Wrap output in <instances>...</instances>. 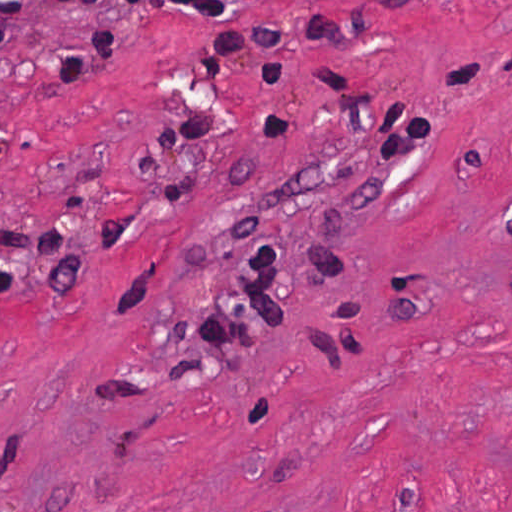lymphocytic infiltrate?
<instances>
[{"label": "lymphocytic infiltrate", "mask_w": 512, "mask_h": 512, "mask_svg": "<svg viewBox=\"0 0 512 512\" xmlns=\"http://www.w3.org/2000/svg\"><path fill=\"white\" fill-rule=\"evenodd\" d=\"M67 4L133 0H60ZM169 6L186 15L216 16L232 23L249 11L238 8L231 0H167ZM22 0H0V83L9 71V44L19 16ZM135 46L111 30L93 33L74 57L60 69V76L71 88H78L107 62ZM286 268L275 250L263 245L250 247V276L247 294L256 310V318L241 316L234 326L222 319H200L198 331L214 343H228L235 328L253 333L262 322L269 330L282 334L288 329V311L283 301ZM283 322H274L282 321Z\"/></svg>", "instance_id": "1"}]
</instances>
